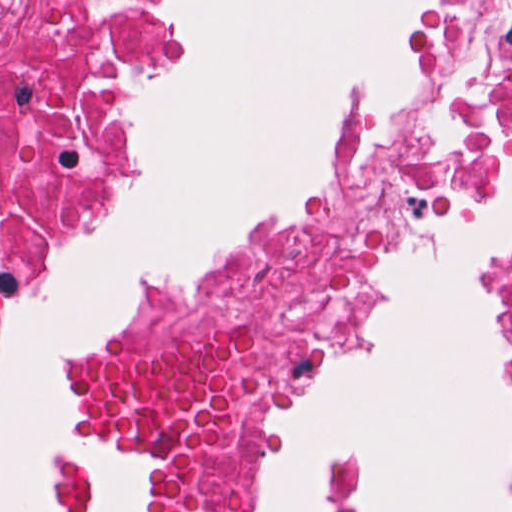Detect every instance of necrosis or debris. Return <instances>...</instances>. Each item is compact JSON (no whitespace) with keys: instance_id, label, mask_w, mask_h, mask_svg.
Returning <instances> with one entry per match:
<instances>
[{"instance_id":"1","label":"necrosis or debris","mask_w":512,"mask_h":512,"mask_svg":"<svg viewBox=\"0 0 512 512\" xmlns=\"http://www.w3.org/2000/svg\"><path fill=\"white\" fill-rule=\"evenodd\" d=\"M205 9L0 0V273L100 174L145 70ZM510 125L512 0H451L420 97L368 120L340 195L109 342L89 374L86 413L162 458L145 512H223L252 375Z\"/></svg>"}]
</instances>
